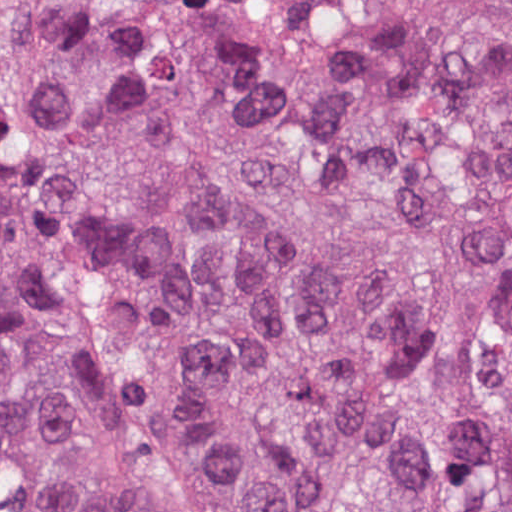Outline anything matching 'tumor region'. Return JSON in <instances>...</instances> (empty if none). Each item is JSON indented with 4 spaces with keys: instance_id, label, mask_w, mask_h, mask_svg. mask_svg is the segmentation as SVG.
Masks as SVG:
<instances>
[{
    "instance_id": "1",
    "label": "tumor region",
    "mask_w": 512,
    "mask_h": 512,
    "mask_svg": "<svg viewBox=\"0 0 512 512\" xmlns=\"http://www.w3.org/2000/svg\"><path fill=\"white\" fill-rule=\"evenodd\" d=\"M0 512H512V0H0Z\"/></svg>"
}]
</instances>
